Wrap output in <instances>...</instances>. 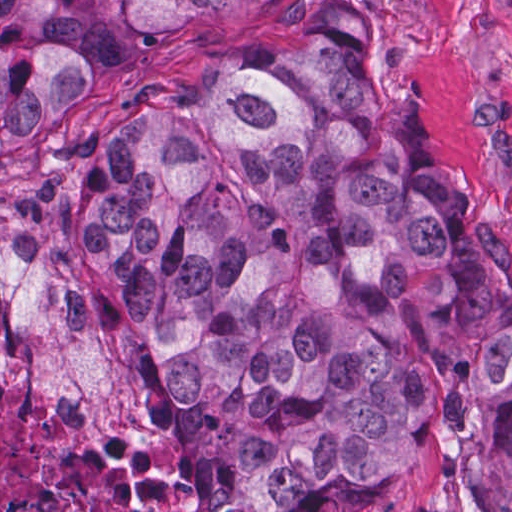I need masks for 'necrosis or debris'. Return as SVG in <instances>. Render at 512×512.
<instances>
[{
    "label": "necrosis or debris",
    "instance_id": "1",
    "mask_svg": "<svg viewBox=\"0 0 512 512\" xmlns=\"http://www.w3.org/2000/svg\"><path fill=\"white\" fill-rule=\"evenodd\" d=\"M0 512H191L143 440L54 379L0 377Z\"/></svg>",
    "mask_w": 512,
    "mask_h": 512
}]
</instances>
